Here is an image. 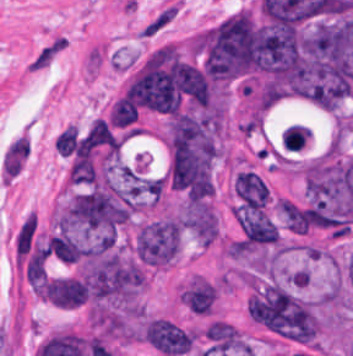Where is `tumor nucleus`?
Instances as JSON below:
<instances>
[{"instance_id": "2f306a5c", "label": "tumor nucleus", "mask_w": 353, "mask_h": 356, "mask_svg": "<svg viewBox=\"0 0 353 356\" xmlns=\"http://www.w3.org/2000/svg\"><path fill=\"white\" fill-rule=\"evenodd\" d=\"M192 53L207 74L221 82L251 76L258 69V25L247 10L191 37Z\"/></svg>"}, {"instance_id": "8643909e", "label": "tumor nucleus", "mask_w": 353, "mask_h": 356, "mask_svg": "<svg viewBox=\"0 0 353 356\" xmlns=\"http://www.w3.org/2000/svg\"><path fill=\"white\" fill-rule=\"evenodd\" d=\"M181 234L182 222L177 217L149 221L137 232L136 254L144 264L169 265L180 253Z\"/></svg>"}, {"instance_id": "5ab6c2c4", "label": "tumor nucleus", "mask_w": 353, "mask_h": 356, "mask_svg": "<svg viewBox=\"0 0 353 356\" xmlns=\"http://www.w3.org/2000/svg\"><path fill=\"white\" fill-rule=\"evenodd\" d=\"M141 335L154 349L168 356L185 355L193 344L192 330L163 314H149Z\"/></svg>"}, {"instance_id": "2cbd58db", "label": "tumor nucleus", "mask_w": 353, "mask_h": 356, "mask_svg": "<svg viewBox=\"0 0 353 356\" xmlns=\"http://www.w3.org/2000/svg\"><path fill=\"white\" fill-rule=\"evenodd\" d=\"M234 218L246 242L250 244L278 242L279 235L275 224L266 212L244 204L235 210Z\"/></svg>"}, {"instance_id": "3d1891a8", "label": "tumor nucleus", "mask_w": 353, "mask_h": 356, "mask_svg": "<svg viewBox=\"0 0 353 356\" xmlns=\"http://www.w3.org/2000/svg\"><path fill=\"white\" fill-rule=\"evenodd\" d=\"M85 287L70 275H61L42 281V297L57 307H77Z\"/></svg>"}, {"instance_id": "2083b535", "label": "tumor nucleus", "mask_w": 353, "mask_h": 356, "mask_svg": "<svg viewBox=\"0 0 353 356\" xmlns=\"http://www.w3.org/2000/svg\"><path fill=\"white\" fill-rule=\"evenodd\" d=\"M235 194L249 207L265 208L269 193L260 174L251 169L236 172L234 181Z\"/></svg>"}, {"instance_id": "8087334f", "label": "tumor nucleus", "mask_w": 353, "mask_h": 356, "mask_svg": "<svg viewBox=\"0 0 353 356\" xmlns=\"http://www.w3.org/2000/svg\"><path fill=\"white\" fill-rule=\"evenodd\" d=\"M179 298L198 313H210L217 299V289L203 276L193 275L180 292Z\"/></svg>"}, {"instance_id": "c2bd9aea", "label": "tumor nucleus", "mask_w": 353, "mask_h": 356, "mask_svg": "<svg viewBox=\"0 0 353 356\" xmlns=\"http://www.w3.org/2000/svg\"><path fill=\"white\" fill-rule=\"evenodd\" d=\"M81 143L118 153L120 140L105 119L95 117Z\"/></svg>"}, {"instance_id": "feef74b5", "label": "tumor nucleus", "mask_w": 353, "mask_h": 356, "mask_svg": "<svg viewBox=\"0 0 353 356\" xmlns=\"http://www.w3.org/2000/svg\"><path fill=\"white\" fill-rule=\"evenodd\" d=\"M110 124L126 126L138 119L136 103L126 92L113 104L109 113Z\"/></svg>"}, {"instance_id": "3e47fb67", "label": "tumor nucleus", "mask_w": 353, "mask_h": 356, "mask_svg": "<svg viewBox=\"0 0 353 356\" xmlns=\"http://www.w3.org/2000/svg\"><path fill=\"white\" fill-rule=\"evenodd\" d=\"M56 148L60 153L71 154L78 148L77 124H70L56 137Z\"/></svg>"}]
</instances>
